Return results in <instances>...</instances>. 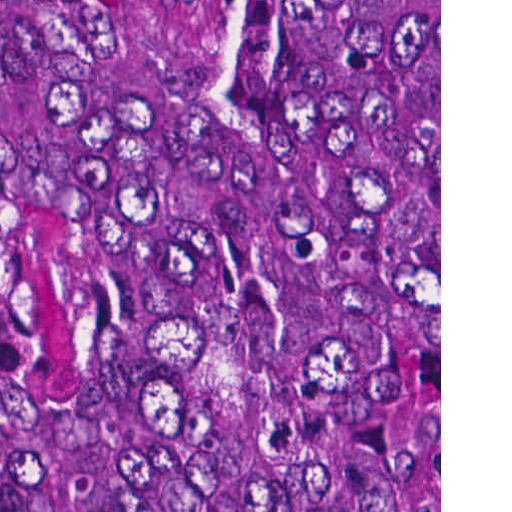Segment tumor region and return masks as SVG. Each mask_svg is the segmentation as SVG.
I'll return each instance as SVG.
<instances>
[{"label": "tumor region", "mask_w": 512, "mask_h": 512, "mask_svg": "<svg viewBox=\"0 0 512 512\" xmlns=\"http://www.w3.org/2000/svg\"><path fill=\"white\" fill-rule=\"evenodd\" d=\"M248 16L345 220L126 197L136 0H0V512H439V0Z\"/></svg>", "instance_id": "e687c5a6"}]
</instances>
